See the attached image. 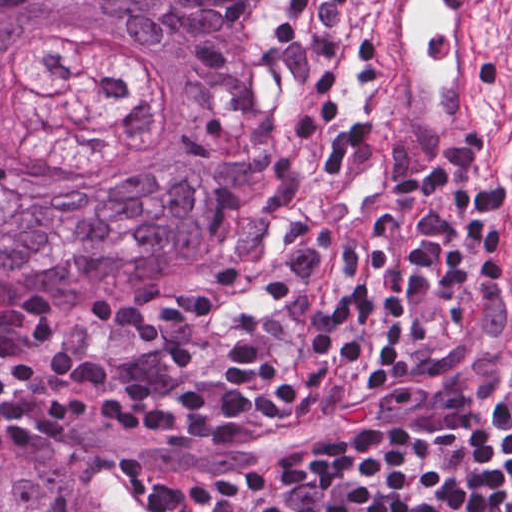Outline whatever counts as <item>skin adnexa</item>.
I'll return each mask as SVG.
<instances>
[{
    "label": "skin adnexa",
    "mask_w": 512,
    "mask_h": 512,
    "mask_svg": "<svg viewBox=\"0 0 512 512\" xmlns=\"http://www.w3.org/2000/svg\"><path fill=\"white\" fill-rule=\"evenodd\" d=\"M276 0H0V310L114 290L248 207ZM0 512H138L65 455L0 450Z\"/></svg>",
    "instance_id": "1"
}]
</instances>
